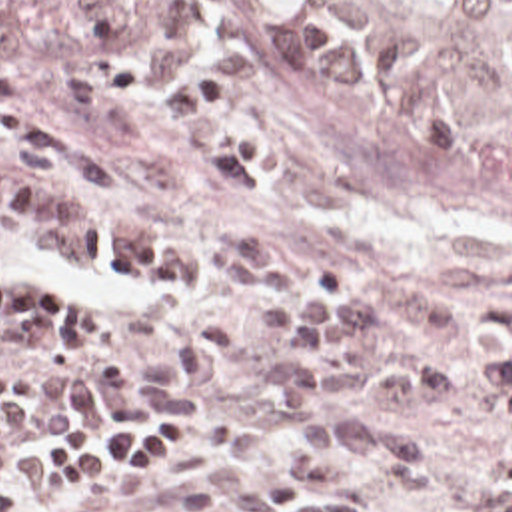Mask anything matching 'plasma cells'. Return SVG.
Listing matches in <instances>:
<instances>
[{
  "instance_id": "plasma-cells-1",
  "label": "plasma cells",
  "mask_w": 512,
  "mask_h": 512,
  "mask_svg": "<svg viewBox=\"0 0 512 512\" xmlns=\"http://www.w3.org/2000/svg\"><path fill=\"white\" fill-rule=\"evenodd\" d=\"M59 179L93 195L111 193L99 155L57 119L0 95V237L39 245L77 271L131 289H185L205 255L73 215L45 189ZM205 337L185 339L175 361L147 371L101 353L87 371L0 377V439L23 435H119L197 423L209 413L205 391L237 367V327L203 317ZM381 459L399 489L423 493L441 471L435 447L407 429L365 413L297 415L273 473L241 491L233 512H351L355 501L325 493L343 481L341 457ZM497 483H512L497 469ZM512 512V493L463 511Z\"/></svg>"
}]
</instances>
